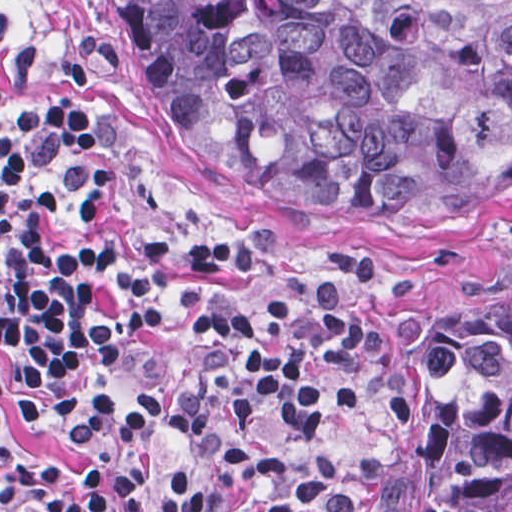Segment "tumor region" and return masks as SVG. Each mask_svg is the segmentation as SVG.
Here are the masks:
<instances>
[{
  "mask_svg": "<svg viewBox=\"0 0 512 512\" xmlns=\"http://www.w3.org/2000/svg\"><path fill=\"white\" fill-rule=\"evenodd\" d=\"M151 119L289 228L512 211V0H118ZM398 454L359 512H512V279L383 320Z\"/></svg>",
  "mask_w": 512,
  "mask_h": 512,
  "instance_id": "obj_1",
  "label": "tumor region"
}]
</instances>
